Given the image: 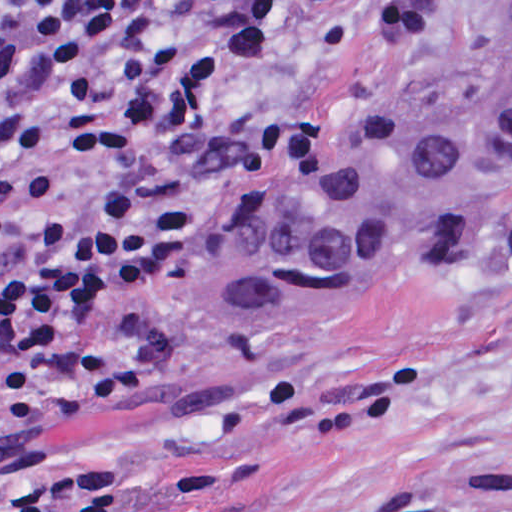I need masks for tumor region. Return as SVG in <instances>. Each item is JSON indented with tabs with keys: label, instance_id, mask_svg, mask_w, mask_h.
<instances>
[{
	"label": "tumor region",
	"instance_id": "tumor-region-1",
	"mask_svg": "<svg viewBox=\"0 0 512 512\" xmlns=\"http://www.w3.org/2000/svg\"><path fill=\"white\" fill-rule=\"evenodd\" d=\"M511 152L512 19L432 71L339 171L194 261L193 329L208 349H228L241 330L351 292L392 252L471 213Z\"/></svg>",
	"mask_w": 512,
	"mask_h": 512
}]
</instances>
